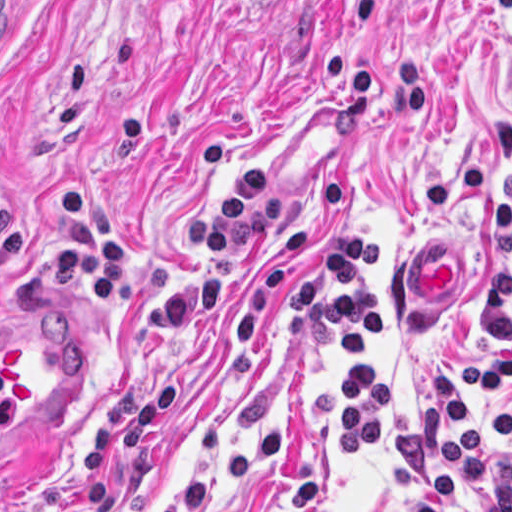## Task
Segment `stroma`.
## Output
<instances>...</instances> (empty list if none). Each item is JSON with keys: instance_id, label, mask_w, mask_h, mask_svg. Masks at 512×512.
I'll use <instances>...</instances> for the list:
<instances>
[{"instance_id": "1", "label": "stroma", "mask_w": 512, "mask_h": 512, "mask_svg": "<svg viewBox=\"0 0 512 512\" xmlns=\"http://www.w3.org/2000/svg\"><path fill=\"white\" fill-rule=\"evenodd\" d=\"M384 230V455L345 473L339 336L272 313L323 234ZM512 223V0H12L0 347L67 335L80 399L0 512H413L395 435L486 338ZM463 254L418 317L416 241ZM507 394L512 401V384Z\"/></svg>"}]
</instances>
